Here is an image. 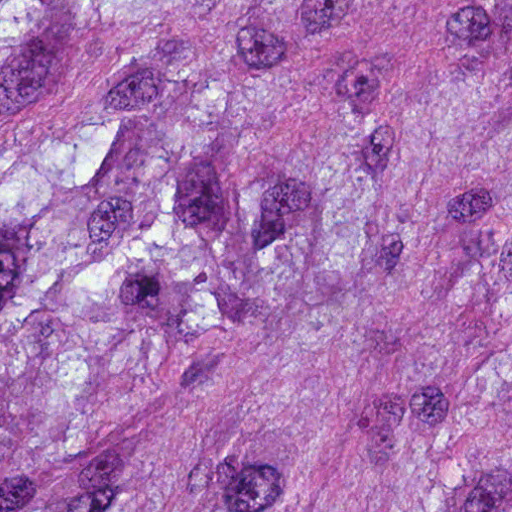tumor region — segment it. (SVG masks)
Wrapping results in <instances>:
<instances>
[{"label":"tumor region","instance_id":"e687c5a6","mask_svg":"<svg viewBox=\"0 0 512 512\" xmlns=\"http://www.w3.org/2000/svg\"><path fill=\"white\" fill-rule=\"evenodd\" d=\"M0 512H512V0H0Z\"/></svg>","mask_w":512,"mask_h":512}]
</instances>
